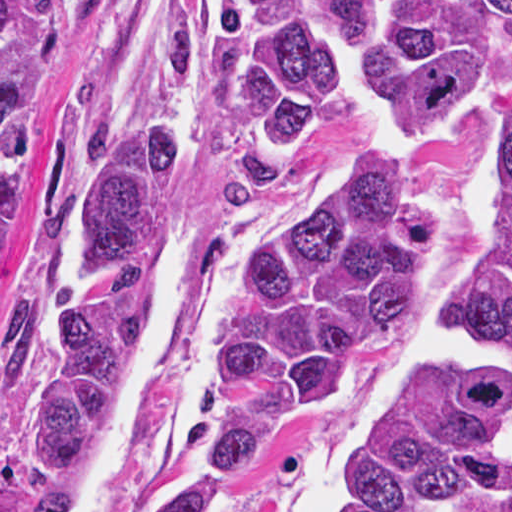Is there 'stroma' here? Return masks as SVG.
I'll list each match as a JSON object with an SVG mask.
<instances>
[{
    "label": "stroma",
    "instance_id": "obj_1",
    "mask_svg": "<svg viewBox=\"0 0 512 512\" xmlns=\"http://www.w3.org/2000/svg\"><path fill=\"white\" fill-rule=\"evenodd\" d=\"M223 1L63 0L59 90L47 133L22 172L11 209L46 234L66 199L73 145L91 114L117 99L182 103L187 165L169 239L198 244L200 254L150 376L124 512H164L222 421L217 330L253 249L312 186L398 140L385 135L377 88L362 79L342 83L287 179L261 196L225 193L208 102L211 45ZM499 163L500 117L489 110L460 117L427 137L420 174L442 195L450 214L435 260L345 398L296 434L275 440L249 467L236 512H289L310 459L361 401L377 369L399 352L415 322L439 317L484 247ZM52 335L34 326L0 376V512H71V480L45 477L30 461L26 444L28 404ZM436 512H512V482L485 499H452Z\"/></svg>",
    "mask_w": 512,
    "mask_h": 512
}]
</instances>
